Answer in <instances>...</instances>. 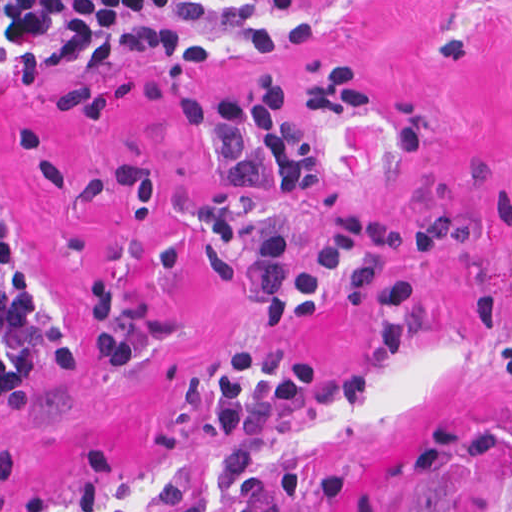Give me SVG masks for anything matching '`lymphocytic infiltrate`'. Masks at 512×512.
I'll use <instances>...</instances> for the list:
<instances>
[{"mask_svg": "<svg viewBox=\"0 0 512 512\" xmlns=\"http://www.w3.org/2000/svg\"><path fill=\"white\" fill-rule=\"evenodd\" d=\"M197 26H240L253 46L278 41L263 11L232 2L1 0V76L43 79L76 54L126 60L220 50V39L191 29ZM365 104L361 68L336 61L303 80L260 81L215 108L218 118L246 133L269 161L283 195H310L321 169L292 119V107L354 110ZM413 228L402 212L346 211L299 276L289 274L290 242L282 229L265 232L256 250L241 257V276L268 326L265 334L238 344L211 397V428L223 448L222 499L215 507L197 483L171 477L164 484L166 512H275L249 483L254 464L243 436L273 427L313 395L345 404L375 390L370 378L324 376L320 366L280 342L289 318L307 322L319 314L335 282L340 305H383L376 336L385 352L398 357L417 350L419 281L389 266ZM70 352V330L1 234V402L39 367ZM304 491L303 476L286 474L278 512H298Z\"/></svg>", "mask_w": 512, "mask_h": 512, "instance_id": "f902f5d3", "label": "lymphocytic infiltrate"}]
</instances>
